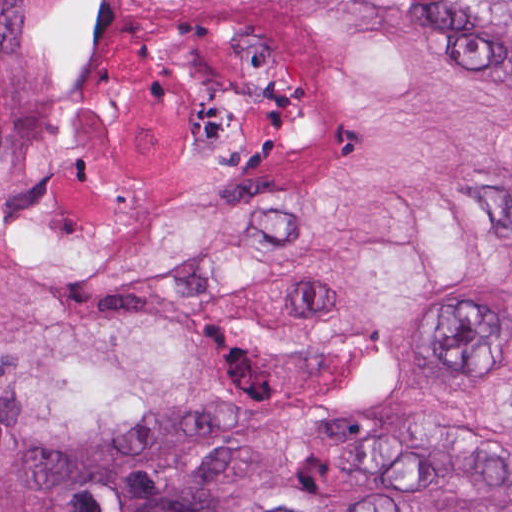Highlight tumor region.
Instances as JSON below:
<instances>
[{
    "mask_svg": "<svg viewBox=\"0 0 512 512\" xmlns=\"http://www.w3.org/2000/svg\"><path fill=\"white\" fill-rule=\"evenodd\" d=\"M1 512H512V0H0Z\"/></svg>",
    "mask_w": 512,
    "mask_h": 512,
    "instance_id": "tumor-region-1",
    "label": "tumor region"
}]
</instances>
